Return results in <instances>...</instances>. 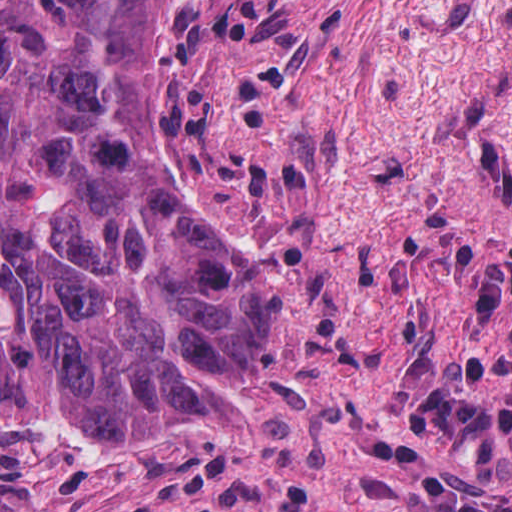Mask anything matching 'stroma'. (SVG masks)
Wrapping results in <instances>:
<instances>
[{"label":"stroma","mask_w":512,"mask_h":512,"mask_svg":"<svg viewBox=\"0 0 512 512\" xmlns=\"http://www.w3.org/2000/svg\"><path fill=\"white\" fill-rule=\"evenodd\" d=\"M1 1H166L156 151L283 292L250 434L1 423ZM0 512H512V0H0Z\"/></svg>","instance_id":"35a3bbf8"}]
</instances>
